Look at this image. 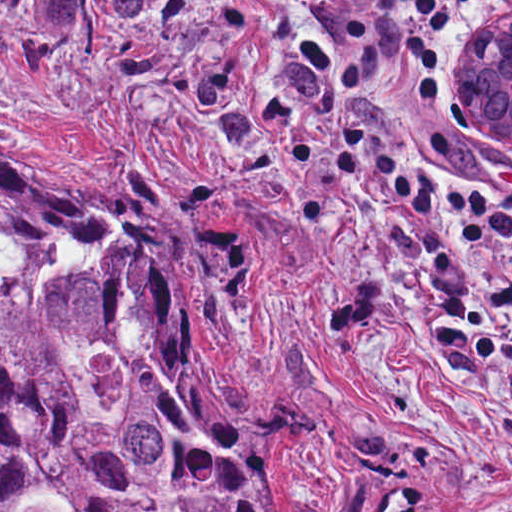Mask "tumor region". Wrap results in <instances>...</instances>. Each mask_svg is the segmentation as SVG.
I'll return each mask as SVG.
<instances>
[{
	"instance_id": "obj_1",
	"label": "tumor region",
	"mask_w": 512,
	"mask_h": 512,
	"mask_svg": "<svg viewBox=\"0 0 512 512\" xmlns=\"http://www.w3.org/2000/svg\"><path fill=\"white\" fill-rule=\"evenodd\" d=\"M459 117L512 142L465 73ZM219 334L214 263L157 206L0 162V512H282L209 400Z\"/></svg>"
}]
</instances>
